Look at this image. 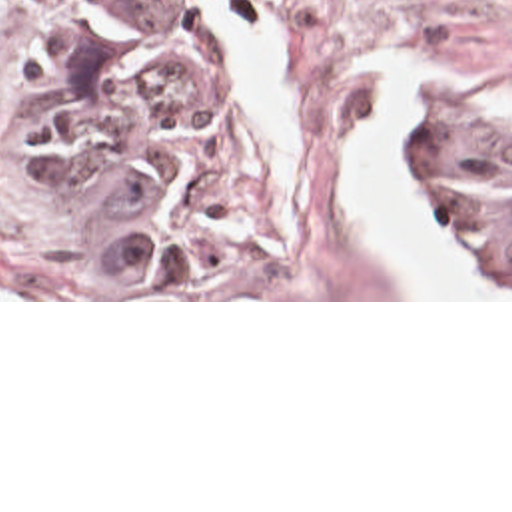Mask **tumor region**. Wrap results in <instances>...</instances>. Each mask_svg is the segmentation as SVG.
Instances as JSON below:
<instances>
[{
	"instance_id": "tumor-region-1",
	"label": "tumor region",
	"mask_w": 512,
	"mask_h": 512,
	"mask_svg": "<svg viewBox=\"0 0 512 512\" xmlns=\"http://www.w3.org/2000/svg\"><path fill=\"white\" fill-rule=\"evenodd\" d=\"M3 160L123 298H251L293 246V132L195 1H67ZM403 172L512 298V142L417 92Z\"/></svg>"
}]
</instances>
